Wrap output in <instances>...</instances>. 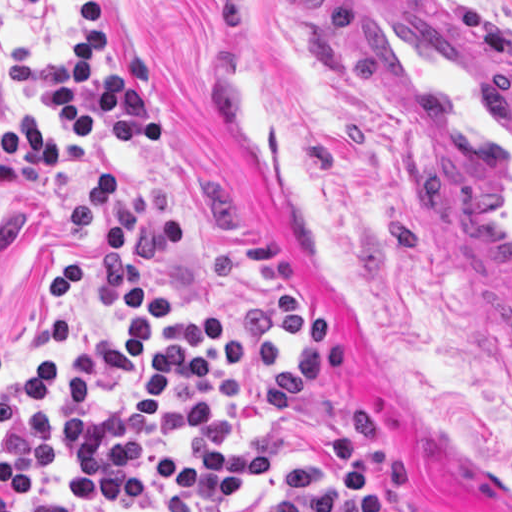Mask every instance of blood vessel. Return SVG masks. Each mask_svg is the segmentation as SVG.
Masks as SVG:
<instances>
[{"label": "blood vessel", "mask_w": 512, "mask_h": 512, "mask_svg": "<svg viewBox=\"0 0 512 512\" xmlns=\"http://www.w3.org/2000/svg\"><path fill=\"white\" fill-rule=\"evenodd\" d=\"M373 117L512 343V56L434 0H335Z\"/></svg>", "instance_id": "1"}]
</instances>
